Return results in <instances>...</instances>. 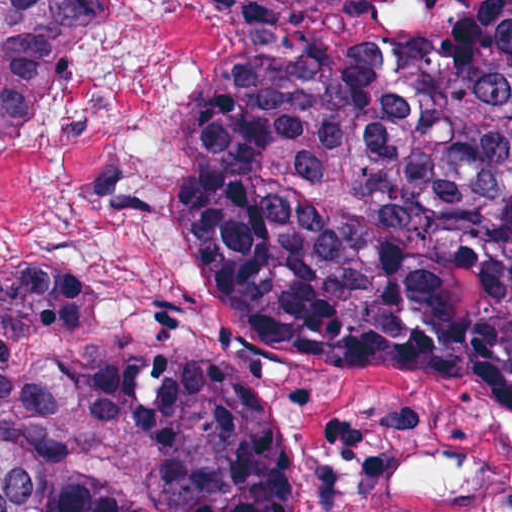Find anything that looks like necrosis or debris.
Segmentation results:
<instances>
[{
  "mask_svg": "<svg viewBox=\"0 0 512 512\" xmlns=\"http://www.w3.org/2000/svg\"><path fill=\"white\" fill-rule=\"evenodd\" d=\"M218 29L219 1H95L68 65L0 133V271L78 283L133 354L221 335L191 246V128Z\"/></svg>",
  "mask_w": 512,
  "mask_h": 512,
  "instance_id": "4bbe7bcc",
  "label": "necrosis or debris"
}]
</instances>
